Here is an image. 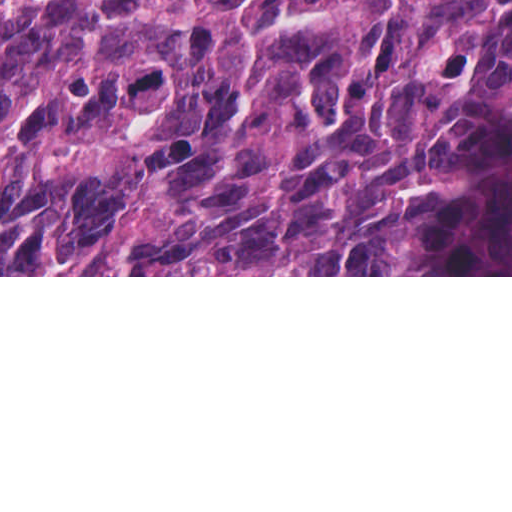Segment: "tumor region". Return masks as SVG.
<instances>
[{
	"instance_id": "e687c5a6",
	"label": "tumor region",
	"mask_w": 512,
	"mask_h": 512,
	"mask_svg": "<svg viewBox=\"0 0 512 512\" xmlns=\"http://www.w3.org/2000/svg\"><path fill=\"white\" fill-rule=\"evenodd\" d=\"M483 0H0V275H415Z\"/></svg>"
}]
</instances>
